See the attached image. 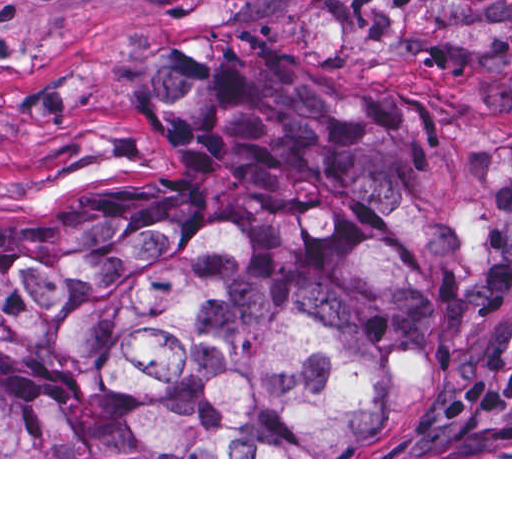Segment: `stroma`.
Listing matches in <instances>:
<instances>
[{
	"instance_id": "stroma-1",
	"label": "stroma",
	"mask_w": 512,
	"mask_h": 512,
	"mask_svg": "<svg viewBox=\"0 0 512 512\" xmlns=\"http://www.w3.org/2000/svg\"><path fill=\"white\" fill-rule=\"evenodd\" d=\"M239 33L323 92L512 118V0H0V459H512L382 457L508 329L512 260L416 397L378 398L340 457H1V209L73 211L117 181L162 174L175 157L136 89L143 48L201 53Z\"/></svg>"
}]
</instances>
